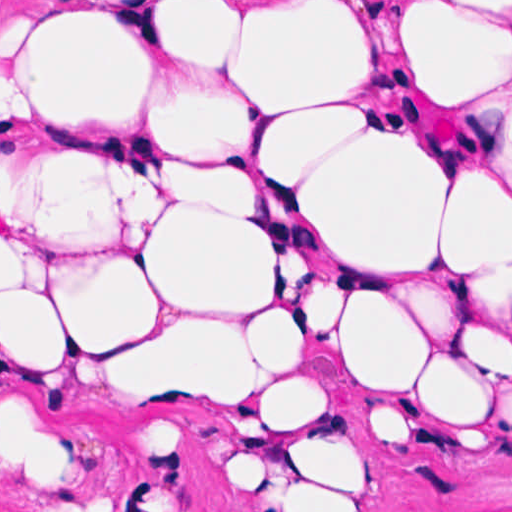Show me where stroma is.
I'll use <instances>...</instances> for the list:
<instances>
[{
	"label": "stroma",
	"instance_id": "35a3bbf8",
	"mask_svg": "<svg viewBox=\"0 0 512 512\" xmlns=\"http://www.w3.org/2000/svg\"><path fill=\"white\" fill-rule=\"evenodd\" d=\"M38 1H512V0H0ZM0 35V53L17 33ZM250 90V89H249ZM265 120V104L250 90ZM5 104L0 102V107ZM330 257L304 242L310 307ZM351 473L339 512H512V385L485 421L436 415L351 381L300 338ZM64 421L75 448L72 483L55 512H249L242 457L218 403L161 375L139 398L107 391L20 357L0 332V400ZM0 512H36L0 467Z\"/></svg>",
	"mask_w": 512,
	"mask_h": 512
}]
</instances>
